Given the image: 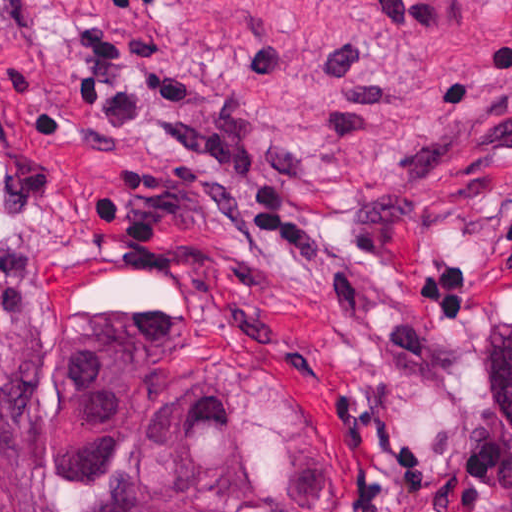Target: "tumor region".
I'll return each instance as SVG.
<instances>
[{
  "mask_svg": "<svg viewBox=\"0 0 512 512\" xmlns=\"http://www.w3.org/2000/svg\"><path fill=\"white\" fill-rule=\"evenodd\" d=\"M41 439L67 512H294L224 398L185 391L158 424L135 425L106 348L75 349L55 363ZM0 512H40L1 443ZM490 512H512V491Z\"/></svg>",
  "mask_w": 512,
  "mask_h": 512,
  "instance_id": "e687c5a6",
  "label": "tumor region"
}]
</instances>
